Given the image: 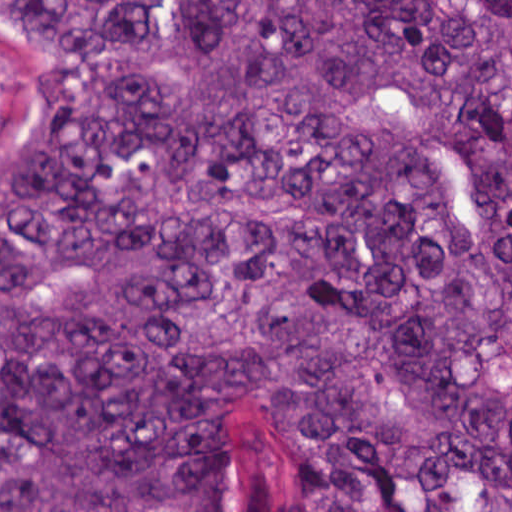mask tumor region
Masks as SVG:
<instances>
[{
    "instance_id": "1",
    "label": "tumor region",
    "mask_w": 512,
    "mask_h": 512,
    "mask_svg": "<svg viewBox=\"0 0 512 512\" xmlns=\"http://www.w3.org/2000/svg\"><path fill=\"white\" fill-rule=\"evenodd\" d=\"M0 14V512H512V0Z\"/></svg>"
}]
</instances>
